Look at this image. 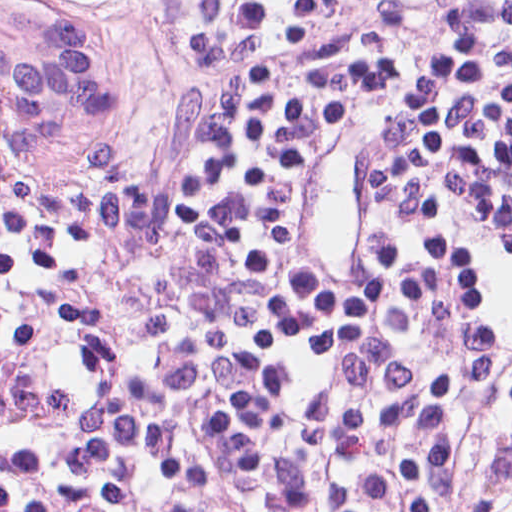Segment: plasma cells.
Returning a JSON list of instances; mask_svg holds the SVG:
<instances>
[{
  "label": "plasma cells",
  "instance_id": "9512152a",
  "mask_svg": "<svg viewBox=\"0 0 512 512\" xmlns=\"http://www.w3.org/2000/svg\"><path fill=\"white\" fill-rule=\"evenodd\" d=\"M287 59L252 82L188 229L83 249L0 215V512H431V371L397 378L331 460L282 448L256 410L269 224L325 104V64Z\"/></svg>",
  "mask_w": 512,
  "mask_h": 512
}]
</instances>
